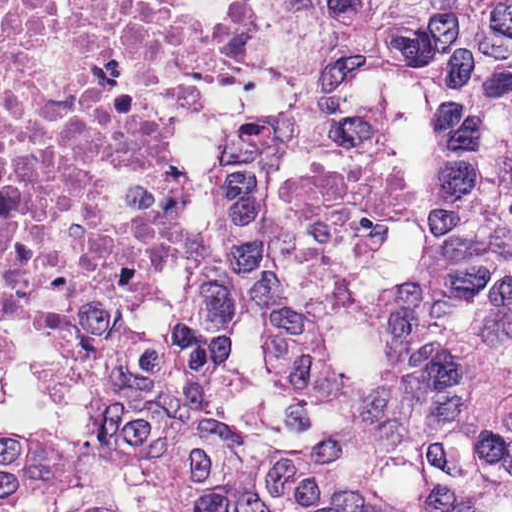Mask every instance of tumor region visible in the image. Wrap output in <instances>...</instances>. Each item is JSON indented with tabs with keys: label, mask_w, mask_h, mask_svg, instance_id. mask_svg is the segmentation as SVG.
Wrapping results in <instances>:
<instances>
[{
	"label": "tumor region",
	"mask_w": 512,
	"mask_h": 512,
	"mask_svg": "<svg viewBox=\"0 0 512 512\" xmlns=\"http://www.w3.org/2000/svg\"><path fill=\"white\" fill-rule=\"evenodd\" d=\"M512 5V0L454 1L397 13L385 53L394 57Z\"/></svg>",
	"instance_id": "obj_1"
}]
</instances>
